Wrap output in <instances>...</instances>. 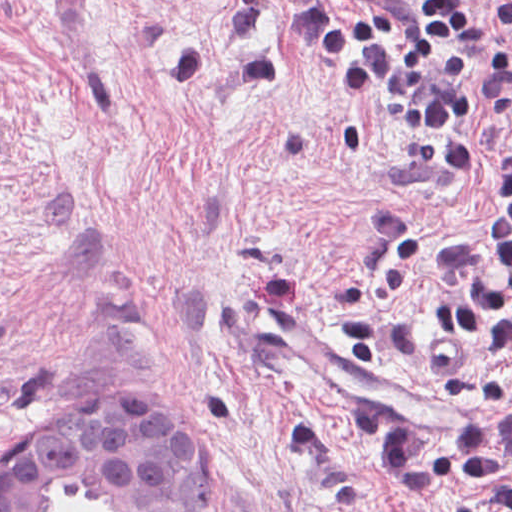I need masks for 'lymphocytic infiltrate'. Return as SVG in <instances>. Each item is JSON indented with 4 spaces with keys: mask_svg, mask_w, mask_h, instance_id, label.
I'll list each match as a JSON object with an SVG mask.
<instances>
[{
    "mask_svg": "<svg viewBox=\"0 0 512 512\" xmlns=\"http://www.w3.org/2000/svg\"><path fill=\"white\" fill-rule=\"evenodd\" d=\"M485 9L505 23L510 42L487 97L494 213L442 260L423 259L422 232L412 218L377 216L384 258L340 296L353 364L422 362L425 343L414 321L386 295L407 287L413 274L439 281L448 295L432 313L435 366L443 377L459 380L490 347L512 364V0H288L291 49L343 87L352 112L378 110L406 127L414 148L406 172L443 184H461L468 172ZM384 479L400 505L443 489L512 512V380L472 395L469 430L456 438L405 434L386 456Z\"/></svg>",
    "mask_w": 512,
    "mask_h": 512,
    "instance_id": "1",
    "label": "lymphocytic infiltrate"
}]
</instances>
